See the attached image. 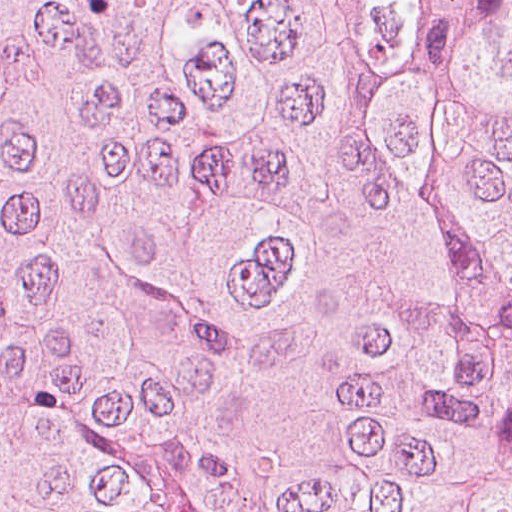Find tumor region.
<instances>
[{"mask_svg":"<svg viewBox=\"0 0 512 512\" xmlns=\"http://www.w3.org/2000/svg\"><path fill=\"white\" fill-rule=\"evenodd\" d=\"M0 512H512V0H0Z\"/></svg>","mask_w":512,"mask_h":512,"instance_id":"1","label":"tumor region"}]
</instances>
